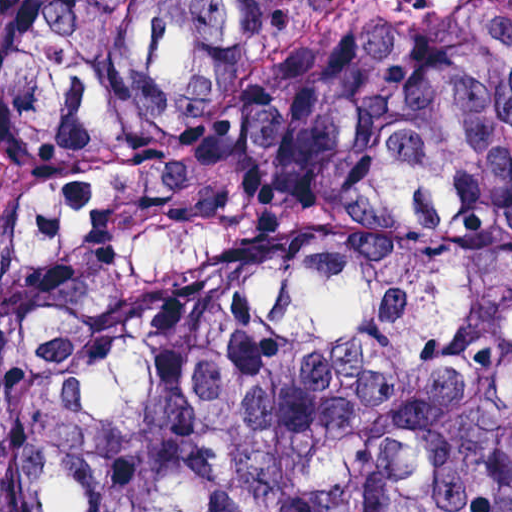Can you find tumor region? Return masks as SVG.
<instances>
[{"label": "tumor region", "mask_w": 512, "mask_h": 512, "mask_svg": "<svg viewBox=\"0 0 512 512\" xmlns=\"http://www.w3.org/2000/svg\"><path fill=\"white\" fill-rule=\"evenodd\" d=\"M0 512H512V0H0Z\"/></svg>", "instance_id": "1"}]
</instances>
